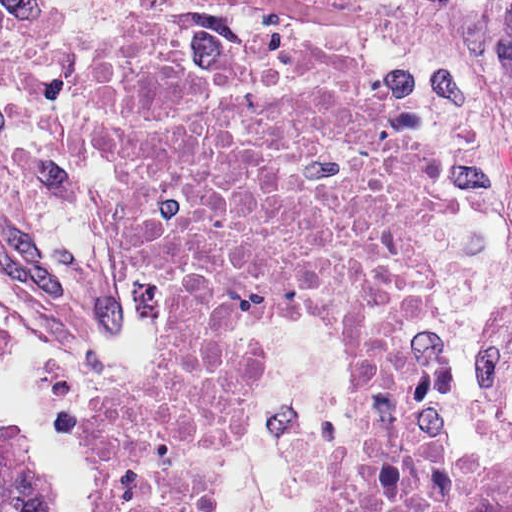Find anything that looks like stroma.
Here are the masks:
<instances>
[{
	"label": "stroma",
	"mask_w": 512,
	"mask_h": 512,
	"mask_svg": "<svg viewBox=\"0 0 512 512\" xmlns=\"http://www.w3.org/2000/svg\"><path fill=\"white\" fill-rule=\"evenodd\" d=\"M158 9L394 63L413 80L440 175L429 228L452 330L448 431L492 442L512 487V181L431 0H0V421L32 429L57 512H108L92 414L152 365L151 307L111 254L80 83L102 42ZM240 335L259 342L224 512H306L287 481V430L315 410L322 430H345L353 350L330 321L292 313L254 319Z\"/></svg>",
	"instance_id": "1"
}]
</instances>
